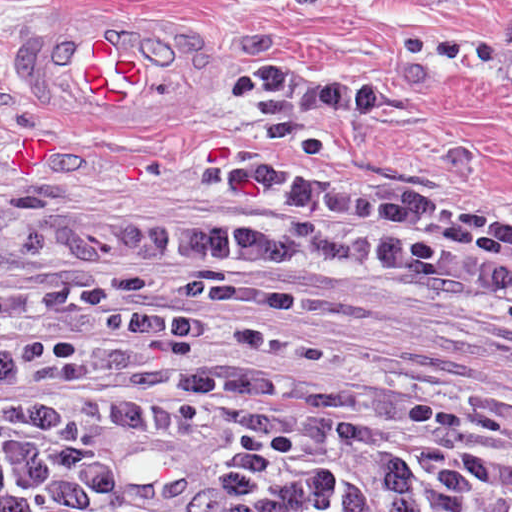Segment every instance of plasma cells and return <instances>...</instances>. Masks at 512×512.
<instances>
[{
	"label": "plasma cells",
	"mask_w": 512,
	"mask_h": 512,
	"mask_svg": "<svg viewBox=\"0 0 512 512\" xmlns=\"http://www.w3.org/2000/svg\"><path fill=\"white\" fill-rule=\"evenodd\" d=\"M225 171L191 236L0 222V512H512L486 427L322 397L289 274L509 293L512 234Z\"/></svg>",
	"instance_id": "plasma-cells-1"
}]
</instances>
